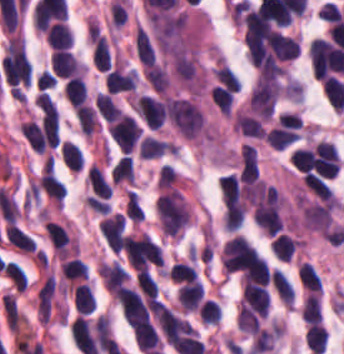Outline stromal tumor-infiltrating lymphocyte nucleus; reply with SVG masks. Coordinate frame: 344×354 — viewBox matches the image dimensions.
<instances>
[{"label":"stromal tumor-infiltrating lymphocyte nucleus","instance_id":"bc302bb0","mask_svg":"<svg viewBox=\"0 0 344 354\" xmlns=\"http://www.w3.org/2000/svg\"><path fill=\"white\" fill-rule=\"evenodd\" d=\"M166 113L176 129L188 140H197L201 137L204 120L196 101L187 96L168 95Z\"/></svg>","mask_w":344,"mask_h":354},{"label":"stromal tumor-infiltrating lymphocyte nucleus","instance_id":"52c7bb5b","mask_svg":"<svg viewBox=\"0 0 344 354\" xmlns=\"http://www.w3.org/2000/svg\"><path fill=\"white\" fill-rule=\"evenodd\" d=\"M155 210L161 229L171 236H179L191 219L180 191L172 186L159 195Z\"/></svg>","mask_w":344,"mask_h":354},{"label":"stromal tumor-infiltrating lymphocyte nucleus","instance_id":"3290ff9b","mask_svg":"<svg viewBox=\"0 0 344 354\" xmlns=\"http://www.w3.org/2000/svg\"><path fill=\"white\" fill-rule=\"evenodd\" d=\"M135 102L139 114L147 125L157 129L166 119L164 103L159 96L140 92Z\"/></svg>","mask_w":344,"mask_h":354},{"label":"stromal tumor-infiltrating lymphocyte nucleus","instance_id":"abfb95fc","mask_svg":"<svg viewBox=\"0 0 344 354\" xmlns=\"http://www.w3.org/2000/svg\"><path fill=\"white\" fill-rule=\"evenodd\" d=\"M218 187L225 206L242 216L245 212V202L240 179L231 173L222 175Z\"/></svg>","mask_w":344,"mask_h":354},{"label":"stromal tumor-infiltrating lymphocyte nucleus","instance_id":"9ea309e8","mask_svg":"<svg viewBox=\"0 0 344 354\" xmlns=\"http://www.w3.org/2000/svg\"><path fill=\"white\" fill-rule=\"evenodd\" d=\"M137 83L136 70L118 64L104 77V87L116 93L134 91L137 88Z\"/></svg>","mask_w":344,"mask_h":354},{"label":"stromal tumor-infiltrating lymphocyte nucleus","instance_id":"f3e2335f","mask_svg":"<svg viewBox=\"0 0 344 354\" xmlns=\"http://www.w3.org/2000/svg\"><path fill=\"white\" fill-rule=\"evenodd\" d=\"M52 68L56 75H83L84 64L68 49H54Z\"/></svg>","mask_w":344,"mask_h":354},{"label":"stromal tumor-infiltrating lymphocyte nucleus","instance_id":"4f13568d","mask_svg":"<svg viewBox=\"0 0 344 354\" xmlns=\"http://www.w3.org/2000/svg\"><path fill=\"white\" fill-rule=\"evenodd\" d=\"M239 176L242 181L253 183L258 176L257 152L255 145L244 142L240 148Z\"/></svg>","mask_w":344,"mask_h":354},{"label":"stromal tumor-infiltrating lymphocyte nucleus","instance_id":"2a367800","mask_svg":"<svg viewBox=\"0 0 344 354\" xmlns=\"http://www.w3.org/2000/svg\"><path fill=\"white\" fill-rule=\"evenodd\" d=\"M73 305L79 314H89L97 308L92 284L81 282L73 287Z\"/></svg>","mask_w":344,"mask_h":354},{"label":"stromal tumor-infiltrating lymphocyte nucleus","instance_id":"4803ca6d","mask_svg":"<svg viewBox=\"0 0 344 354\" xmlns=\"http://www.w3.org/2000/svg\"><path fill=\"white\" fill-rule=\"evenodd\" d=\"M44 231L53 249L68 253L72 241L65 227L52 220H44Z\"/></svg>","mask_w":344,"mask_h":354},{"label":"stromal tumor-infiltrating lymphocyte nucleus","instance_id":"4245b91a","mask_svg":"<svg viewBox=\"0 0 344 354\" xmlns=\"http://www.w3.org/2000/svg\"><path fill=\"white\" fill-rule=\"evenodd\" d=\"M64 97L72 106H77L83 102L88 96L87 82L78 72L67 77L63 85Z\"/></svg>","mask_w":344,"mask_h":354},{"label":"stromal tumor-infiltrating lymphocyte nucleus","instance_id":"4c9ddf68","mask_svg":"<svg viewBox=\"0 0 344 354\" xmlns=\"http://www.w3.org/2000/svg\"><path fill=\"white\" fill-rule=\"evenodd\" d=\"M47 42L57 48H68L73 43V32L64 20H57L48 27Z\"/></svg>","mask_w":344,"mask_h":354},{"label":"stromal tumor-infiltrating lymphocyte nucleus","instance_id":"2761f720","mask_svg":"<svg viewBox=\"0 0 344 354\" xmlns=\"http://www.w3.org/2000/svg\"><path fill=\"white\" fill-rule=\"evenodd\" d=\"M272 285L277 296L285 305L293 304L295 300V289L286 273L281 268L271 270Z\"/></svg>","mask_w":344,"mask_h":354},{"label":"stromal tumor-infiltrating lymphocyte nucleus","instance_id":"3c572f05","mask_svg":"<svg viewBox=\"0 0 344 354\" xmlns=\"http://www.w3.org/2000/svg\"><path fill=\"white\" fill-rule=\"evenodd\" d=\"M8 329L18 332L24 319V315L12 293H6L1 299Z\"/></svg>","mask_w":344,"mask_h":354},{"label":"stromal tumor-infiltrating lymphocyte nucleus","instance_id":"42bb06b2","mask_svg":"<svg viewBox=\"0 0 344 354\" xmlns=\"http://www.w3.org/2000/svg\"><path fill=\"white\" fill-rule=\"evenodd\" d=\"M61 272L63 279L73 285L88 274V265L76 255L62 260Z\"/></svg>","mask_w":344,"mask_h":354},{"label":"stromal tumor-infiltrating lymphocyte nucleus","instance_id":"9e4306bb","mask_svg":"<svg viewBox=\"0 0 344 354\" xmlns=\"http://www.w3.org/2000/svg\"><path fill=\"white\" fill-rule=\"evenodd\" d=\"M297 246L298 239L286 233H279L273 238L270 250L275 258L290 261Z\"/></svg>","mask_w":344,"mask_h":354},{"label":"stromal tumor-infiltrating lymphocyte nucleus","instance_id":"04cf8593","mask_svg":"<svg viewBox=\"0 0 344 354\" xmlns=\"http://www.w3.org/2000/svg\"><path fill=\"white\" fill-rule=\"evenodd\" d=\"M79 129L86 135L91 136L99 129L100 123L95 109L89 103H82L76 108Z\"/></svg>","mask_w":344,"mask_h":354},{"label":"stromal tumor-infiltrating lymphocyte nucleus","instance_id":"e9af9c67","mask_svg":"<svg viewBox=\"0 0 344 354\" xmlns=\"http://www.w3.org/2000/svg\"><path fill=\"white\" fill-rule=\"evenodd\" d=\"M297 275L307 290L322 293V278L317 269L307 261H303L298 268Z\"/></svg>","mask_w":344,"mask_h":354},{"label":"stromal tumor-infiltrating lymphocyte nucleus","instance_id":"782c7336","mask_svg":"<svg viewBox=\"0 0 344 354\" xmlns=\"http://www.w3.org/2000/svg\"><path fill=\"white\" fill-rule=\"evenodd\" d=\"M111 180L118 184H133L134 169L133 160L126 153L121 155L113 165L111 172Z\"/></svg>","mask_w":344,"mask_h":354},{"label":"stromal tumor-infiltrating lymphocyte nucleus","instance_id":"cac63f63","mask_svg":"<svg viewBox=\"0 0 344 354\" xmlns=\"http://www.w3.org/2000/svg\"><path fill=\"white\" fill-rule=\"evenodd\" d=\"M213 104L221 114L228 115L231 112L233 95L227 84L215 83L210 87Z\"/></svg>","mask_w":344,"mask_h":354},{"label":"stromal tumor-infiltrating lymphocyte nucleus","instance_id":"2e467ee5","mask_svg":"<svg viewBox=\"0 0 344 354\" xmlns=\"http://www.w3.org/2000/svg\"><path fill=\"white\" fill-rule=\"evenodd\" d=\"M93 64L99 70H107L109 66V46L106 38L99 31L92 41Z\"/></svg>","mask_w":344,"mask_h":354},{"label":"stromal tumor-infiltrating lymphocyte nucleus","instance_id":"7eef579d","mask_svg":"<svg viewBox=\"0 0 344 354\" xmlns=\"http://www.w3.org/2000/svg\"><path fill=\"white\" fill-rule=\"evenodd\" d=\"M327 331L325 325L310 323L306 329V344L312 354H319L326 346Z\"/></svg>","mask_w":344,"mask_h":354},{"label":"stromal tumor-infiltrating lymphocyte nucleus","instance_id":"c26a33f6","mask_svg":"<svg viewBox=\"0 0 344 354\" xmlns=\"http://www.w3.org/2000/svg\"><path fill=\"white\" fill-rule=\"evenodd\" d=\"M168 276L178 283L197 280V270L186 260L177 259L168 269Z\"/></svg>","mask_w":344,"mask_h":354},{"label":"stromal tumor-infiltrating lymphocyte nucleus","instance_id":"3e0999b9","mask_svg":"<svg viewBox=\"0 0 344 354\" xmlns=\"http://www.w3.org/2000/svg\"><path fill=\"white\" fill-rule=\"evenodd\" d=\"M212 72L217 82L236 92L241 88L240 79L224 60L218 59Z\"/></svg>","mask_w":344,"mask_h":354},{"label":"stromal tumor-infiltrating lymphocyte nucleus","instance_id":"a0a3295f","mask_svg":"<svg viewBox=\"0 0 344 354\" xmlns=\"http://www.w3.org/2000/svg\"><path fill=\"white\" fill-rule=\"evenodd\" d=\"M322 314L321 294H307L301 307V316L310 324L320 321Z\"/></svg>","mask_w":344,"mask_h":354},{"label":"stromal tumor-infiltrating lymphocyte nucleus","instance_id":"b6af03f8","mask_svg":"<svg viewBox=\"0 0 344 354\" xmlns=\"http://www.w3.org/2000/svg\"><path fill=\"white\" fill-rule=\"evenodd\" d=\"M222 309L213 298H205L198 305V318L203 324H217L221 319Z\"/></svg>","mask_w":344,"mask_h":354},{"label":"stromal tumor-infiltrating lymphocyte nucleus","instance_id":"6c763739","mask_svg":"<svg viewBox=\"0 0 344 354\" xmlns=\"http://www.w3.org/2000/svg\"><path fill=\"white\" fill-rule=\"evenodd\" d=\"M167 151V140L146 134L141 140L140 155L141 157H156Z\"/></svg>","mask_w":344,"mask_h":354},{"label":"stromal tumor-infiltrating lymphocyte nucleus","instance_id":"fa64b396","mask_svg":"<svg viewBox=\"0 0 344 354\" xmlns=\"http://www.w3.org/2000/svg\"><path fill=\"white\" fill-rule=\"evenodd\" d=\"M290 161L296 169L307 172L313 166L311 146L297 145L290 154Z\"/></svg>","mask_w":344,"mask_h":354},{"label":"stromal tumor-infiltrating lymphocyte nucleus","instance_id":"21d57d70","mask_svg":"<svg viewBox=\"0 0 344 354\" xmlns=\"http://www.w3.org/2000/svg\"><path fill=\"white\" fill-rule=\"evenodd\" d=\"M94 106L104 119L113 114L117 106V102L112 92L97 90L95 95Z\"/></svg>","mask_w":344,"mask_h":354},{"label":"stromal tumor-infiltrating lymphocyte nucleus","instance_id":"02f42fee","mask_svg":"<svg viewBox=\"0 0 344 354\" xmlns=\"http://www.w3.org/2000/svg\"><path fill=\"white\" fill-rule=\"evenodd\" d=\"M125 213L127 217L140 221L143 219L144 210L136 190L129 189L126 193Z\"/></svg>","mask_w":344,"mask_h":354},{"label":"stromal tumor-infiltrating lymphocyte nucleus","instance_id":"18da8d3c","mask_svg":"<svg viewBox=\"0 0 344 354\" xmlns=\"http://www.w3.org/2000/svg\"><path fill=\"white\" fill-rule=\"evenodd\" d=\"M178 173L172 165L162 164L157 173V190H166L177 180Z\"/></svg>","mask_w":344,"mask_h":354},{"label":"stromal tumor-infiltrating lymphocyte nucleus","instance_id":"8379cbfb","mask_svg":"<svg viewBox=\"0 0 344 354\" xmlns=\"http://www.w3.org/2000/svg\"><path fill=\"white\" fill-rule=\"evenodd\" d=\"M246 204L228 209L223 221L227 231H236L240 228L245 216Z\"/></svg>","mask_w":344,"mask_h":354},{"label":"stromal tumor-infiltrating lymphocyte nucleus","instance_id":"023d44f5","mask_svg":"<svg viewBox=\"0 0 344 354\" xmlns=\"http://www.w3.org/2000/svg\"><path fill=\"white\" fill-rule=\"evenodd\" d=\"M34 102L47 114L56 115L58 107L52 97L45 91H38L34 97Z\"/></svg>","mask_w":344,"mask_h":354},{"label":"stromal tumor-infiltrating lymphocyte nucleus","instance_id":"afbf053c","mask_svg":"<svg viewBox=\"0 0 344 354\" xmlns=\"http://www.w3.org/2000/svg\"><path fill=\"white\" fill-rule=\"evenodd\" d=\"M55 86V75L50 69H43L36 76V87L39 90Z\"/></svg>","mask_w":344,"mask_h":354}]
</instances>
